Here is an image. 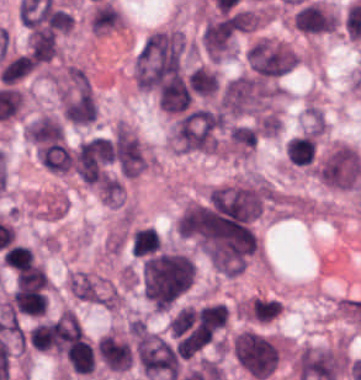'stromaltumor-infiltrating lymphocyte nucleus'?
<instances>
[{
	"label": "stromal tumor-infiltrating lymphocyte nucleus",
	"mask_w": 361,
	"mask_h": 380,
	"mask_svg": "<svg viewBox=\"0 0 361 380\" xmlns=\"http://www.w3.org/2000/svg\"><path fill=\"white\" fill-rule=\"evenodd\" d=\"M13 308L28 315H44L47 299L35 289H15L12 291Z\"/></svg>",
	"instance_id": "stromal-tumor-infiltrating-lymphocyte-nucleus-1"
},
{
	"label": "stromal tumor-infiltrating lymphocyte nucleus",
	"mask_w": 361,
	"mask_h": 380,
	"mask_svg": "<svg viewBox=\"0 0 361 380\" xmlns=\"http://www.w3.org/2000/svg\"><path fill=\"white\" fill-rule=\"evenodd\" d=\"M28 47L33 61L37 62H48L56 51L54 36L44 29L29 33Z\"/></svg>",
	"instance_id": "stromal-tumor-infiltrating-lymphocyte-nucleus-2"
},
{
	"label": "stromal tumor-infiltrating lymphocyte nucleus",
	"mask_w": 361,
	"mask_h": 380,
	"mask_svg": "<svg viewBox=\"0 0 361 380\" xmlns=\"http://www.w3.org/2000/svg\"><path fill=\"white\" fill-rule=\"evenodd\" d=\"M244 315L251 321L270 322L280 312L275 300L266 298H253L241 306Z\"/></svg>",
	"instance_id": "stromal-tumor-infiltrating-lymphocyte-nucleus-3"
},
{
	"label": "stromal tumor-infiltrating lymphocyte nucleus",
	"mask_w": 361,
	"mask_h": 380,
	"mask_svg": "<svg viewBox=\"0 0 361 380\" xmlns=\"http://www.w3.org/2000/svg\"><path fill=\"white\" fill-rule=\"evenodd\" d=\"M187 85L200 95L212 96L217 89V74L204 67H197L187 77Z\"/></svg>",
	"instance_id": "stromal-tumor-infiltrating-lymphocyte-nucleus-4"
},
{
	"label": "stromal tumor-infiltrating lymphocyte nucleus",
	"mask_w": 361,
	"mask_h": 380,
	"mask_svg": "<svg viewBox=\"0 0 361 380\" xmlns=\"http://www.w3.org/2000/svg\"><path fill=\"white\" fill-rule=\"evenodd\" d=\"M34 68V62L27 54H20L2 67L0 83L13 84Z\"/></svg>",
	"instance_id": "stromal-tumor-infiltrating-lymphocyte-nucleus-5"
},
{
	"label": "stromal tumor-infiltrating lymphocyte nucleus",
	"mask_w": 361,
	"mask_h": 380,
	"mask_svg": "<svg viewBox=\"0 0 361 380\" xmlns=\"http://www.w3.org/2000/svg\"><path fill=\"white\" fill-rule=\"evenodd\" d=\"M310 137L293 136L286 142V157L294 164H305L312 154Z\"/></svg>",
	"instance_id": "stromal-tumor-infiltrating-lymphocyte-nucleus-6"
},
{
	"label": "stromal tumor-infiltrating lymphocyte nucleus",
	"mask_w": 361,
	"mask_h": 380,
	"mask_svg": "<svg viewBox=\"0 0 361 380\" xmlns=\"http://www.w3.org/2000/svg\"><path fill=\"white\" fill-rule=\"evenodd\" d=\"M159 241L160 238L155 229L148 226L135 229L131 243V254L136 257L150 252L157 247Z\"/></svg>",
	"instance_id": "stromal-tumor-infiltrating-lymphocyte-nucleus-7"
}]
</instances>
